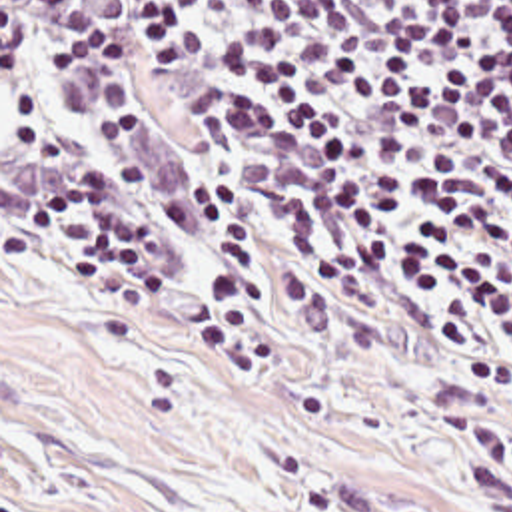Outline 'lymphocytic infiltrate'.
Returning <instances> with one entry per match:
<instances>
[{
  "instance_id": "1",
  "label": "lymphocytic infiltrate",
  "mask_w": 512,
  "mask_h": 512,
  "mask_svg": "<svg viewBox=\"0 0 512 512\" xmlns=\"http://www.w3.org/2000/svg\"><path fill=\"white\" fill-rule=\"evenodd\" d=\"M28 9L56 271L512 398V0Z\"/></svg>"
}]
</instances>
